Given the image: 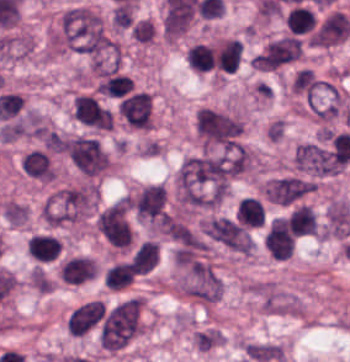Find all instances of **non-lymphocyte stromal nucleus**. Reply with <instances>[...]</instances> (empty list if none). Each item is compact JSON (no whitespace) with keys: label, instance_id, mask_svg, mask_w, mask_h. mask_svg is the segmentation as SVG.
Returning <instances> with one entry per match:
<instances>
[{"label":"non-lymphocyte stromal nucleus","instance_id":"obj_1","mask_svg":"<svg viewBox=\"0 0 350 362\" xmlns=\"http://www.w3.org/2000/svg\"><path fill=\"white\" fill-rule=\"evenodd\" d=\"M234 174L233 154L200 152L182 161L176 196L182 204L217 205L228 193Z\"/></svg>","mask_w":350,"mask_h":362},{"label":"non-lymphocyte stromal nucleus","instance_id":"obj_2","mask_svg":"<svg viewBox=\"0 0 350 362\" xmlns=\"http://www.w3.org/2000/svg\"><path fill=\"white\" fill-rule=\"evenodd\" d=\"M96 200L95 181L87 179L58 187L46 200L47 225L58 228L91 218Z\"/></svg>","mask_w":350,"mask_h":362},{"label":"non-lymphocyte stromal nucleus","instance_id":"obj_3","mask_svg":"<svg viewBox=\"0 0 350 362\" xmlns=\"http://www.w3.org/2000/svg\"><path fill=\"white\" fill-rule=\"evenodd\" d=\"M244 126L241 113L208 105L198 107L193 117V130L203 146H235Z\"/></svg>","mask_w":350,"mask_h":362},{"label":"non-lymphocyte stromal nucleus","instance_id":"obj_4","mask_svg":"<svg viewBox=\"0 0 350 362\" xmlns=\"http://www.w3.org/2000/svg\"><path fill=\"white\" fill-rule=\"evenodd\" d=\"M176 272L179 287L202 303L220 298L222 280L209 261L190 252H176Z\"/></svg>","mask_w":350,"mask_h":362},{"label":"non-lymphocyte stromal nucleus","instance_id":"obj_5","mask_svg":"<svg viewBox=\"0 0 350 362\" xmlns=\"http://www.w3.org/2000/svg\"><path fill=\"white\" fill-rule=\"evenodd\" d=\"M60 149L83 175L107 168L108 156L101 143L86 135H64Z\"/></svg>","mask_w":350,"mask_h":362},{"label":"non-lymphocyte stromal nucleus","instance_id":"obj_6","mask_svg":"<svg viewBox=\"0 0 350 362\" xmlns=\"http://www.w3.org/2000/svg\"><path fill=\"white\" fill-rule=\"evenodd\" d=\"M262 190L264 200L288 207L302 202L310 193V179L297 172H283L266 179Z\"/></svg>","mask_w":350,"mask_h":362},{"label":"non-lymphocyte stromal nucleus","instance_id":"obj_7","mask_svg":"<svg viewBox=\"0 0 350 362\" xmlns=\"http://www.w3.org/2000/svg\"><path fill=\"white\" fill-rule=\"evenodd\" d=\"M134 218L161 225L169 212L168 196L161 183H148L129 196Z\"/></svg>","mask_w":350,"mask_h":362},{"label":"non-lymphocyte stromal nucleus","instance_id":"obj_8","mask_svg":"<svg viewBox=\"0 0 350 362\" xmlns=\"http://www.w3.org/2000/svg\"><path fill=\"white\" fill-rule=\"evenodd\" d=\"M204 232L229 249L250 252L254 241L246 227L233 219L213 215L202 225Z\"/></svg>","mask_w":350,"mask_h":362},{"label":"non-lymphocyte stromal nucleus","instance_id":"obj_9","mask_svg":"<svg viewBox=\"0 0 350 362\" xmlns=\"http://www.w3.org/2000/svg\"><path fill=\"white\" fill-rule=\"evenodd\" d=\"M299 53V37L285 34L269 42L253 56V69L275 70L297 57Z\"/></svg>","mask_w":350,"mask_h":362},{"label":"non-lymphocyte stromal nucleus","instance_id":"obj_10","mask_svg":"<svg viewBox=\"0 0 350 362\" xmlns=\"http://www.w3.org/2000/svg\"><path fill=\"white\" fill-rule=\"evenodd\" d=\"M96 228L111 245L127 247L130 230L125 204L115 202L97 214Z\"/></svg>","mask_w":350,"mask_h":362},{"label":"non-lymphocyte stromal nucleus","instance_id":"obj_11","mask_svg":"<svg viewBox=\"0 0 350 362\" xmlns=\"http://www.w3.org/2000/svg\"><path fill=\"white\" fill-rule=\"evenodd\" d=\"M242 353L247 362H280L284 358L281 345L267 340H254L244 344Z\"/></svg>","mask_w":350,"mask_h":362},{"label":"non-lymphocyte stromal nucleus","instance_id":"obj_12","mask_svg":"<svg viewBox=\"0 0 350 362\" xmlns=\"http://www.w3.org/2000/svg\"><path fill=\"white\" fill-rule=\"evenodd\" d=\"M0 213L9 226H21L28 217L26 206L12 199H5L1 203Z\"/></svg>","mask_w":350,"mask_h":362}]
</instances>
